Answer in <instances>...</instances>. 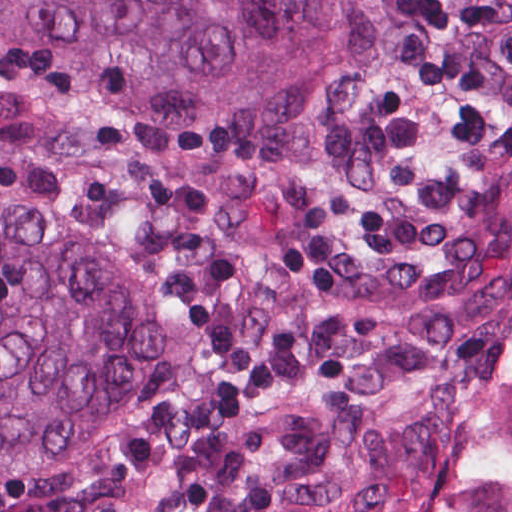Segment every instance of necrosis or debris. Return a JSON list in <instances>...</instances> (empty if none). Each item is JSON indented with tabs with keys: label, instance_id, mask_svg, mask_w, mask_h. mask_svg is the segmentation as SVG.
<instances>
[{
	"label": "necrosis or debris",
	"instance_id": "obj_1",
	"mask_svg": "<svg viewBox=\"0 0 512 512\" xmlns=\"http://www.w3.org/2000/svg\"><path fill=\"white\" fill-rule=\"evenodd\" d=\"M373 512H512V337L435 447Z\"/></svg>",
	"mask_w": 512,
	"mask_h": 512
}]
</instances>
